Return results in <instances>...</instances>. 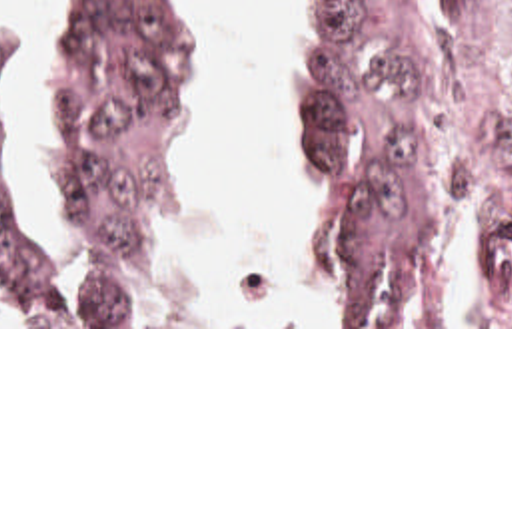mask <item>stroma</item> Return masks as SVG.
Listing matches in <instances>:
<instances>
[{"mask_svg":"<svg viewBox=\"0 0 512 512\" xmlns=\"http://www.w3.org/2000/svg\"><path fill=\"white\" fill-rule=\"evenodd\" d=\"M304 61L290 87L298 89L308 65V24L304 0H290ZM196 8V97L178 129L168 169V201L160 213V253L156 269V325H0V329H512L490 325L462 293V213L474 181V151L484 133L512 121V4L508 0H428L414 36L416 115L432 163L438 193L444 201V291L434 309V325H342L332 303L318 285L324 309L336 325H170L166 315L164 273L170 259V239L182 227L174 183L182 169L188 131L196 101L206 85V8ZM68 0H58V46L50 77V153L58 185L56 217L50 233L38 223L26 193L24 147L26 115L32 107L30 32L24 26H0L14 34L18 59L14 71V149L18 161V193L30 225L48 241L64 247L72 235L68 195L62 175V48L66 40ZM288 97V103H290ZM288 105L278 121L276 141L288 167L292 195L306 221L316 271V221L300 191L294 167L286 155L282 129Z\"/></svg>","mask_w":512,"mask_h":512,"instance_id":"1","label":"stroma"}]
</instances>
